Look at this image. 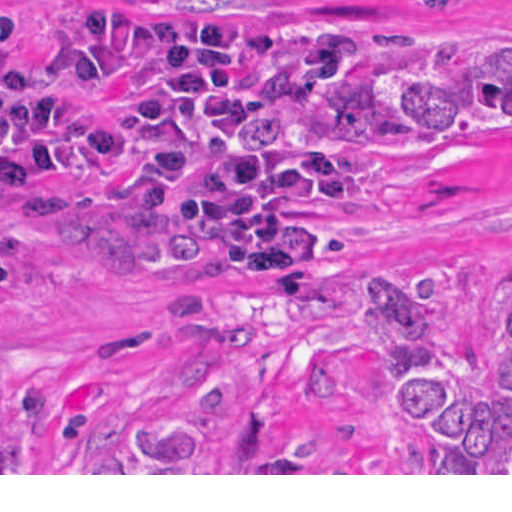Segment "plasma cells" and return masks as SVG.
I'll use <instances>...</instances> for the list:
<instances>
[{
	"instance_id": "9512152a",
	"label": "plasma cells",
	"mask_w": 512,
	"mask_h": 512,
	"mask_svg": "<svg viewBox=\"0 0 512 512\" xmlns=\"http://www.w3.org/2000/svg\"><path fill=\"white\" fill-rule=\"evenodd\" d=\"M350 17H251L123 0H68L61 43L81 72L122 86L109 165L145 185L194 247L256 282L322 294L339 247L336 199L369 169L343 147H254L246 121L315 91L358 51ZM0 180L62 206L72 109L29 89L18 11L0 0Z\"/></svg>"
}]
</instances>
